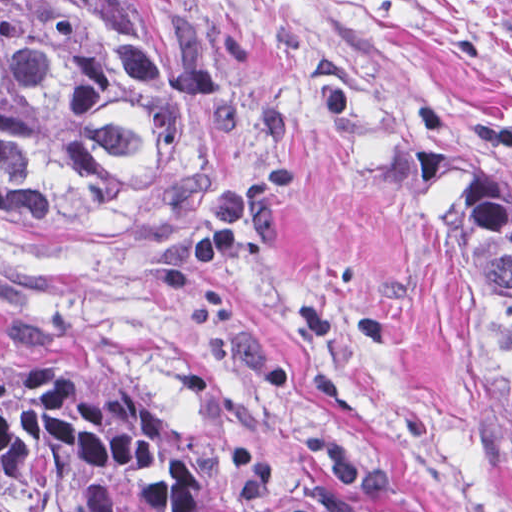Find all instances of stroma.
Masks as SVG:
<instances>
[{
    "mask_svg": "<svg viewBox=\"0 0 512 512\" xmlns=\"http://www.w3.org/2000/svg\"><path fill=\"white\" fill-rule=\"evenodd\" d=\"M215 188L137 234L0 228V376L63 391L240 512H512V418L435 245L512 174V0H176Z\"/></svg>",
    "mask_w": 512,
    "mask_h": 512,
    "instance_id": "stroma-1",
    "label": "stroma"
}]
</instances>
